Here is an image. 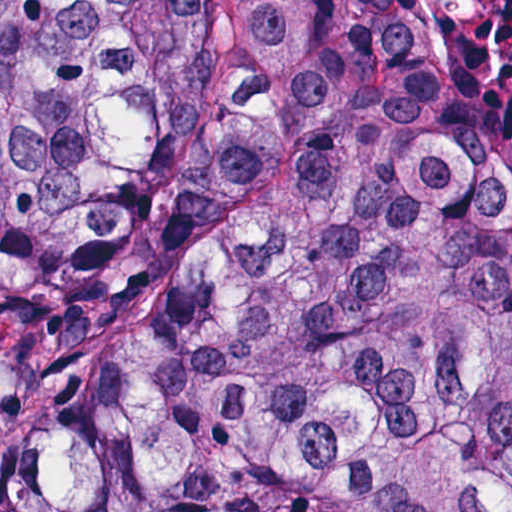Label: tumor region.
I'll return each instance as SVG.
<instances>
[{
  "label": "tumor region",
  "mask_w": 512,
  "mask_h": 512,
  "mask_svg": "<svg viewBox=\"0 0 512 512\" xmlns=\"http://www.w3.org/2000/svg\"><path fill=\"white\" fill-rule=\"evenodd\" d=\"M0 512H512V122L381 0H0Z\"/></svg>",
  "instance_id": "e687c5a6"
}]
</instances>
